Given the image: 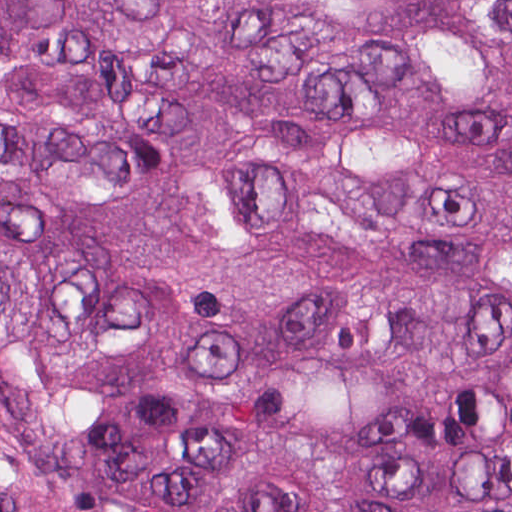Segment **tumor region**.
<instances>
[{
    "instance_id": "e687c5a6",
    "label": "tumor region",
    "mask_w": 512,
    "mask_h": 512,
    "mask_svg": "<svg viewBox=\"0 0 512 512\" xmlns=\"http://www.w3.org/2000/svg\"><path fill=\"white\" fill-rule=\"evenodd\" d=\"M0 512H512V0H0Z\"/></svg>"
}]
</instances>
